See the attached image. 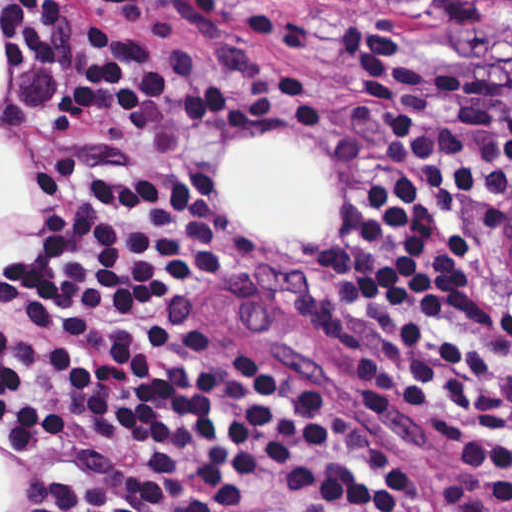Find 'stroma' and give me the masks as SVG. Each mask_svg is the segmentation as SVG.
Masks as SVG:
<instances>
[{
    "instance_id": "1",
    "label": "stroma",
    "mask_w": 512,
    "mask_h": 512,
    "mask_svg": "<svg viewBox=\"0 0 512 512\" xmlns=\"http://www.w3.org/2000/svg\"><path fill=\"white\" fill-rule=\"evenodd\" d=\"M201 13L259 47L269 91L258 114L186 139L150 173L189 176L214 205V251L174 322L199 337L259 342L316 375L359 409L413 466L433 512H512V480L423 428L366 381L341 349L329 283L348 213L377 177L384 134L339 61L336 19L346 6L397 23L448 50L461 64L512 85V39L465 42L442 28L422 0H199ZM11 56L0 0V512H21V473L1 449V262L40 225L46 173L34 158L1 150V112ZM254 136L306 148L335 185V213L307 245L238 235L226 222L217 179L230 150ZM512 191L484 218L473 244L472 319L478 334L512 357V277L503 228Z\"/></svg>"
}]
</instances>
